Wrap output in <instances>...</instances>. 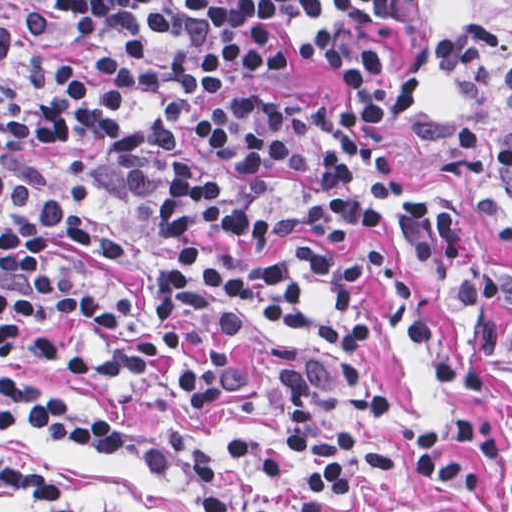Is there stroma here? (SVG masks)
Here are the masks:
<instances>
[{
    "instance_id": "obj_1",
    "label": "stroma",
    "mask_w": 512,
    "mask_h": 512,
    "mask_svg": "<svg viewBox=\"0 0 512 512\" xmlns=\"http://www.w3.org/2000/svg\"><path fill=\"white\" fill-rule=\"evenodd\" d=\"M472 17L508 42L512 35L493 28L446 0H413V48L425 100L411 123L379 124L377 135L393 179L406 183L396 194L433 199L450 206L456 229L476 265L495 274H512V196L495 180L480 152L466 154L459 142L435 140L452 124L471 121L501 140H512V109L495 94L457 95L443 68V40L451 21ZM234 93L258 98L302 96L321 103L333 116L348 95V75L282 47L269 77H242L211 94L186 123L180 144L164 165L163 184L135 192L110 138L104 134L78 145L43 144L31 165L46 184L60 182L62 158L86 163L96 189H112L121 198H100L87 208L89 221L124 247L120 254L61 248L55 264L70 285L103 303L115 294L132 299L126 320L98 328L87 320L60 314L24 326L15 348L1 345V0H0V512L1 448L36 469L67 492L78 506H102L123 512H196L187 475H164L145 468L113 446H80L29 425L1 426V383L28 394H59L102 411L177 434L227 482L286 505H312L324 512H372L358 492L299 464L285 462L283 393L261 368L267 347L286 343L308 356L326 354L314 337L332 308L321 278L295 261V249L309 248L347 259L361 246L387 255L421 295L428 315L450 347L478 371L483 408L496 429L512 435V363L484 347L469 331L457 294L442 275L403 241L361 228L339 235L281 238L259 252L255 264L285 267L304 298V322L286 326L258 313L238 331V365L246 381L231 403L194 409L175 394L150 388L128 376L98 369L108 352L138 343L150 334L157 316L150 277L176 266L183 246L213 255L228 251L207 232L166 240L159 208L171 188L175 164L196 163L230 192L239 188L236 172L194 144L198 121ZM37 339L53 346V358L30 352ZM82 357L84 365L66 362ZM464 413L441 387L428 355L405 339L383 314L373 362V403L367 442L379 450L405 446L424 414L452 419ZM486 493L471 494L445 483L418 478H377L363 469L361 483L376 512H512V492L500 469L479 451Z\"/></svg>"
}]
</instances>
